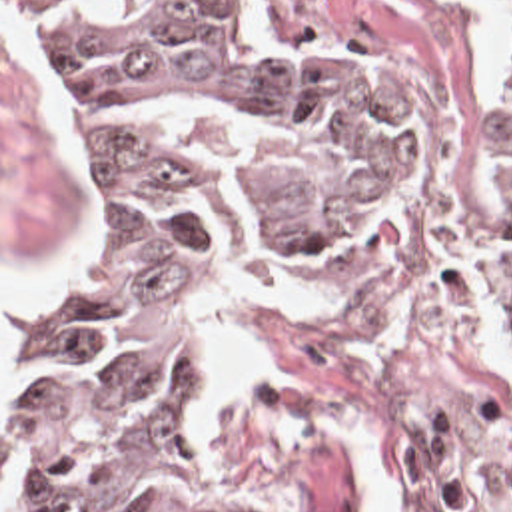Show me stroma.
Masks as SVG:
<instances>
[{
	"label": "stroma",
	"mask_w": 512,
	"mask_h": 512,
	"mask_svg": "<svg viewBox=\"0 0 512 512\" xmlns=\"http://www.w3.org/2000/svg\"><path fill=\"white\" fill-rule=\"evenodd\" d=\"M270 57L383 127L389 213L315 263L260 273L184 327L208 487L238 512H512V309L499 217V89L471 77L477 17L447 0H252ZM80 211V143L46 35L0 0L2 311L56 285ZM313 313L248 307L266 351L230 419L198 429L204 349L268 283Z\"/></svg>",
	"instance_id": "35a3bbf8"
}]
</instances>
